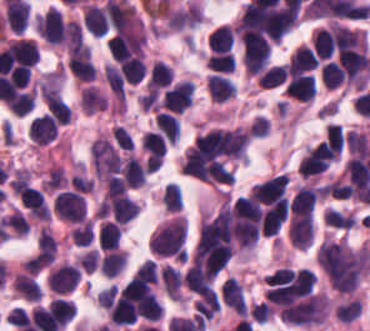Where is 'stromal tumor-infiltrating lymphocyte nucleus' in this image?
<instances>
[{
  "label": "stromal tumor-infiltrating lymphocyte nucleus",
  "instance_id": "obj_10",
  "mask_svg": "<svg viewBox=\"0 0 370 331\" xmlns=\"http://www.w3.org/2000/svg\"><path fill=\"white\" fill-rule=\"evenodd\" d=\"M206 86L211 100L221 103L231 99L236 91V85L231 79L216 72L207 77Z\"/></svg>",
  "mask_w": 370,
  "mask_h": 331
},
{
  "label": "stromal tumor-infiltrating lymphocyte nucleus",
  "instance_id": "obj_32",
  "mask_svg": "<svg viewBox=\"0 0 370 331\" xmlns=\"http://www.w3.org/2000/svg\"><path fill=\"white\" fill-rule=\"evenodd\" d=\"M326 139L331 149L342 151L346 136L341 123H327Z\"/></svg>",
  "mask_w": 370,
  "mask_h": 331
},
{
  "label": "stromal tumor-infiltrating lymphocyte nucleus",
  "instance_id": "obj_2",
  "mask_svg": "<svg viewBox=\"0 0 370 331\" xmlns=\"http://www.w3.org/2000/svg\"><path fill=\"white\" fill-rule=\"evenodd\" d=\"M53 209L64 222L79 223L84 218L85 200L82 193L67 189L54 199Z\"/></svg>",
  "mask_w": 370,
  "mask_h": 331
},
{
  "label": "stromal tumor-infiltrating lymphocyte nucleus",
  "instance_id": "obj_31",
  "mask_svg": "<svg viewBox=\"0 0 370 331\" xmlns=\"http://www.w3.org/2000/svg\"><path fill=\"white\" fill-rule=\"evenodd\" d=\"M94 235L92 221H84L78 224L71 233L74 245L89 247Z\"/></svg>",
  "mask_w": 370,
  "mask_h": 331
},
{
  "label": "stromal tumor-infiltrating lymphocyte nucleus",
  "instance_id": "obj_8",
  "mask_svg": "<svg viewBox=\"0 0 370 331\" xmlns=\"http://www.w3.org/2000/svg\"><path fill=\"white\" fill-rule=\"evenodd\" d=\"M318 200V189L301 186L294 194L289 210L297 217H312Z\"/></svg>",
  "mask_w": 370,
  "mask_h": 331
},
{
  "label": "stromal tumor-infiltrating lymphocyte nucleus",
  "instance_id": "obj_27",
  "mask_svg": "<svg viewBox=\"0 0 370 331\" xmlns=\"http://www.w3.org/2000/svg\"><path fill=\"white\" fill-rule=\"evenodd\" d=\"M47 109L58 123H66L72 112L70 106L57 94H47Z\"/></svg>",
  "mask_w": 370,
  "mask_h": 331
},
{
  "label": "stromal tumor-infiltrating lymphocyte nucleus",
  "instance_id": "obj_19",
  "mask_svg": "<svg viewBox=\"0 0 370 331\" xmlns=\"http://www.w3.org/2000/svg\"><path fill=\"white\" fill-rule=\"evenodd\" d=\"M122 232L119 224L103 220L98 227L97 241L99 248H119Z\"/></svg>",
  "mask_w": 370,
  "mask_h": 331
},
{
  "label": "stromal tumor-infiltrating lymphocyte nucleus",
  "instance_id": "obj_23",
  "mask_svg": "<svg viewBox=\"0 0 370 331\" xmlns=\"http://www.w3.org/2000/svg\"><path fill=\"white\" fill-rule=\"evenodd\" d=\"M35 104V89H22L7 100V107L15 115L26 114Z\"/></svg>",
  "mask_w": 370,
  "mask_h": 331
},
{
  "label": "stromal tumor-infiltrating lymphocyte nucleus",
  "instance_id": "obj_25",
  "mask_svg": "<svg viewBox=\"0 0 370 331\" xmlns=\"http://www.w3.org/2000/svg\"><path fill=\"white\" fill-rule=\"evenodd\" d=\"M291 65L304 70H313L317 66V57L312 47L300 44L295 48L288 60Z\"/></svg>",
  "mask_w": 370,
  "mask_h": 331
},
{
  "label": "stromal tumor-infiltrating lymphocyte nucleus",
  "instance_id": "obj_5",
  "mask_svg": "<svg viewBox=\"0 0 370 331\" xmlns=\"http://www.w3.org/2000/svg\"><path fill=\"white\" fill-rule=\"evenodd\" d=\"M58 133V124L49 113L36 116L29 122L28 134L34 144L44 145L52 141Z\"/></svg>",
  "mask_w": 370,
  "mask_h": 331
},
{
  "label": "stromal tumor-infiltrating lymphocyte nucleus",
  "instance_id": "obj_28",
  "mask_svg": "<svg viewBox=\"0 0 370 331\" xmlns=\"http://www.w3.org/2000/svg\"><path fill=\"white\" fill-rule=\"evenodd\" d=\"M133 281L138 284L154 285L158 280V270L153 259H146L140 263L132 275Z\"/></svg>",
  "mask_w": 370,
  "mask_h": 331
},
{
  "label": "stromal tumor-infiltrating lymphocyte nucleus",
  "instance_id": "obj_1",
  "mask_svg": "<svg viewBox=\"0 0 370 331\" xmlns=\"http://www.w3.org/2000/svg\"><path fill=\"white\" fill-rule=\"evenodd\" d=\"M187 219L175 214L162 222L149 238V250L159 257L185 259Z\"/></svg>",
  "mask_w": 370,
  "mask_h": 331
},
{
  "label": "stromal tumor-infiltrating lymphocyte nucleus",
  "instance_id": "obj_21",
  "mask_svg": "<svg viewBox=\"0 0 370 331\" xmlns=\"http://www.w3.org/2000/svg\"><path fill=\"white\" fill-rule=\"evenodd\" d=\"M172 74L170 65L157 59L151 65L146 88L149 91H158L171 81Z\"/></svg>",
  "mask_w": 370,
  "mask_h": 331
},
{
  "label": "stromal tumor-infiltrating lymphocyte nucleus",
  "instance_id": "obj_11",
  "mask_svg": "<svg viewBox=\"0 0 370 331\" xmlns=\"http://www.w3.org/2000/svg\"><path fill=\"white\" fill-rule=\"evenodd\" d=\"M221 294L225 303L237 314L245 315L247 305L241 284L236 277H228L222 288Z\"/></svg>",
  "mask_w": 370,
  "mask_h": 331
},
{
  "label": "stromal tumor-infiltrating lymphocyte nucleus",
  "instance_id": "obj_26",
  "mask_svg": "<svg viewBox=\"0 0 370 331\" xmlns=\"http://www.w3.org/2000/svg\"><path fill=\"white\" fill-rule=\"evenodd\" d=\"M235 61V56L229 50L211 54L206 59L208 69L218 73H232Z\"/></svg>",
  "mask_w": 370,
  "mask_h": 331
},
{
  "label": "stromal tumor-infiltrating lymphocyte nucleus",
  "instance_id": "obj_34",
  "mask_svg": "<svg viewBox=\"0 0 370 331\" xmlns=\"http://www.w3.org/2000/svg\"><path fill=\"white\" fill-rule=\"evenodd\" d=\"M321 81L330 88L340 86L333 60L321 65Z\"/></svg>",
  "mask_w": 370,
  "mask_h": 331
},
{
  "label": "stromal tumor-infiltrating lymphocyte nucleus",
  "instance_id": "obj_30",
  "mask_svg": "<svg viewBox=\"0 0 370 331\" xmlns=\"http://www.w3.org/2000/svg\"><path fill=\"white\" fill-rule=\"evenodd\" d=\"M162 203L166 212H176L181 209L182 194L177 185L174 183H167L162 192Z\"/></svg>",
  "mask_w": 370,
  "mask_h": 331
},
{
  "label": "stromal tumor-infiltrating lymphocyte nucleus",
  "instance_id": "obj_13",
  "mask_svg": "<svg viewBox=\"0 0 370 331\" xmlns=\"http://www.w3.org/2000/svg\"><path fill=\"white\" fill-rule=\"evenodd\" d=\"M12 287L25 302H39L41 289L35 279L26 272L15 273Z\"/></svg>",
  "mask_w": 370,
  "mask_h": 331
},
{
  "label": "stromal tumor-infiltrating lymphocyte nucleus",
  "instance_id": "obj_15",
  "mask_svg": "<svg viewBox=\"0 0 370 331\" xmlns=\"http://www.w3.org/2000/svg\"><path fill=\"white\" fill-rule=\"evenodd\" d=\"M336 46L334 29L320 28L312 34V47L315 54L321 59H329Z\"/></svg>",
  "mask_w": 370,
  "mask_h": 331
},
{
  "label": "stromal tumor-infiltrating lymphocyte nucleus",
  "instance_id": "obj_6",
  "mask_svg": "<svg viewBox=\"0 0 370 331\" xmlns=\"http://www.w3.org/2000/svg\"><path fill=\"white\" fill-rule=\"evenodd\" d=\"M67 65L73 76L82 81H93L95 67L90 47L72 50L68 57Z\"/></svg>",
  "mask_w": 370,
  "mask_h": 331
},
{
  "label": "stromal tumor-infiltrating lymphocyte nucleus",
  "instance_id": "obj_17",
  "mask_svg": "<svg viewBox=\"0 0 370 331\" xmlns=\"http://www.w3.org/2000/svg\"><path fill=\"white\" fill-rule=\"evenodd\" d=\"M83 16L88 28L92 35H105L108 31L107 19L100 7L94 3H87Z\"/></svg>",
  "mask_w": 370,
  "mask_h": 331
},
{
  "label": "stromal tumor-infiltrating lymphocyte nucleus",
  "instance_id": "obj_24",
  "mask_svg": "<svg viewBox=\"0 0 370 331\" xmlns=\"http://www.w3.org/2000/svg\"><path fill=\"white\" fill-rule=\"evenodd\" d=\"M211 52L229 50L233 45V31L228 24L215 28L207 42Z\"/></svg>",
  "mask_w": 370,
  "mask_h": 331
},
{
  "label": "stromal tumor-infiltrating lymphocyte nucleus",
  "instance_id": "obj_7",
  "mask_svg": "<svg viewBox=\"0 0 370 331\" xmlns=\"http://www.w3.org/2000/svg\"><path fill=\"white\" fill-rule=\"evenodd\" d=\"M48 319L53 329L64 330L74 318L75 303L69 298L57 297L47 307Z\"/></svg>",
  "mask_w": 370,
  "mask_h": 331
},
{
  "label": "stromal tumor-infiltrating lymphocyte nucleus",
  "instance_id": "obj_14",
  "mask_svg": "<svg viewBox=\"0 0 370 331\" xmlns=\"http://www.w3.org/2000/svg\"><path fill=\"white\" fill-rule=\"evenodd\" d=\"M107 94L94 85L84 87L80 97L79 105L84 113H95L107 108Z\"/></svg>",
  "mask_w": 370,
  "mask_h": 331
},
{
  "label": "stromal tumor-infiltrating lymphocyte nucleus",
  "instance_id": "obj_12",
  "mask_svg": "<svg viewBox=\"0 0 370 331\" xmlns=\"http://www.w3.org/2000/svg\"><path fill=\"white\" fill-rule=\"evenodd\" d=\"M161 284L168 296L173 301L182 302L183 278L182 273L170 264H166L159 271Z\"/></svg>",
  "mask_w": 370,
  "mask_h": 331
},
{
  "label": "stromal tumor-infiltrating lymphocyte nucleus",
  "instance_id": "obj_20",
  "mask_svg": "<svg viewBox=\"0 0 370 331\" xmlns=\"http://www.w3.org/2000/svg\"><path fill=\"white\" fill-rule=\"evenodd\" d=\"M65 42L68 51L88 55V43L78 20H71L64 26Z\"/></svg>",
  "mask_w": 370,
  "mask_h": 331
},
{
  "label": "stromal tumor-infiltrating lymphocyte nucleus",
  "instance_id": "obj_18",
  "mask_svg": "<svg viewBox=\"0 0 370 331\" xmlns=\"http://www.w3.org/2000/svg\"><path fill=\"white\" fill-rule=\"evenodd\" d=\"M157 130L168 143H176L179 138V120L170 112L158 110L155 117Z\"/></svg>",
  "mask_w": 370,
  "mask_h": 331
},
{
  "label": "stromal tumor-infiltrating lymphocyte nucleus",
  "instance_id": "obj_29",
  "mask_svg": "<svg viewBox=\"0 0 370 331\" xmlns=\"http://www.w3.org/2000/svg\"><path fill=\"white\" fill-rule=\"evenodd\" d=\"M37 248L38 253L46 259H55L57 239L54 234L44 226L39 230Z\"/></svg>",
  "mask_w": 370,
  "mask_h": 331
},
{
  "label": "stromal tumor-infiltrating lymphocyte nucleus",
  "instance_id": "obj_9",
  "mask_svg": "<svg viewBox=\"0 0 370 331\" xmlns=\"http://www.w3.org/2000/svg\"><path fill=\"white\" fill-rule=\"evenodd\" d=\"M0 53L34 64L39 56V51L34 40L30 38H17L8 40Z\"/></svg>",
  "mask_w": 370,
  "mask_h": 331
},
{
  "label": "stromal tumor-infiltrating lymphocyte nucleus",
  "instance_id": "obj_3",
  "mask_svg": "<svg viewBox=\"0 0 370 331\" xmlns=\"http://www.w3.org/2000/svg\"><path fill=\"white\" fill-rule=\"evenodd\" d=\"M283 90L292 98L310 101L316 92V80L308 73L288 65Z\"/></svg>",
  "mask_w": 370,
  "mask_h": 331
},
{
  "label": "stromal tumor-infiltrating lymphocyte nucleus",
  "instance_id": "obj_16",
  "mask_svg": "<svg viewBox=\"0 0 370 331\" xmlns=\"http://www.w3.org/2000/svg\"><path fill=\"white\" fill-rule=\"evenodd\" d=\"M127 263L125 251L114 248L106 251L99 259V268L107 277H114L122 271Z\"/></svg>",
  "mask_w": 370,
  "mask_h": 331
},
{
  "label": "stromal tumor-infiltrating lymphocyte nucleus",
  "instance_id": "obj_4",
  "mask_svg": "<svg viewBox=\"0 0 370 331\" xmlns=\"http://www.w3.org/2000/svg\"><path fill=\"white\" fill-rule=\"evenodd\" d=\"M79 277L80 271L77 264H57L48 273L47 286L54 294H67L74 290Z\"/></svg>",
  "mask_w": 370,
  "mask_h": 331
},
{
  "label": "stromal tumor-infiltrating lymphocyte nucleus",
  "instance_id": "obj_22",
  "mask_svg": "<svg viewBox=\"0 0 370 331\" xmlns=\"http://www.w3.org/2000/svg\"><path fill=\"white\" fill-rule=\"evenodd\" d=\"M256 79L262 89H273L286 83L288 72L283 65L273 64L258 74Z\"/></svg>",
  "mask_w": 370,
  "mask_h": 331
},
{
  "label": "stromal tumor-infiltrating lymphocyte nucleus",
  "instance_id": "obj_33",
  "mask_svg": "<svg viewBox=\"0 0 370 331\" xmlns=\"http://www.w3.org/2000/svg\"><path fill=\"white\" fill-rule=\"evenodd\" d=\"M248 309L252 321L255 322L266 323L273 316L272 310L263 301L252 303Z\"/></svg>",
  "mask_w": 370,
  "mask_h": 331
}]
</instances>
